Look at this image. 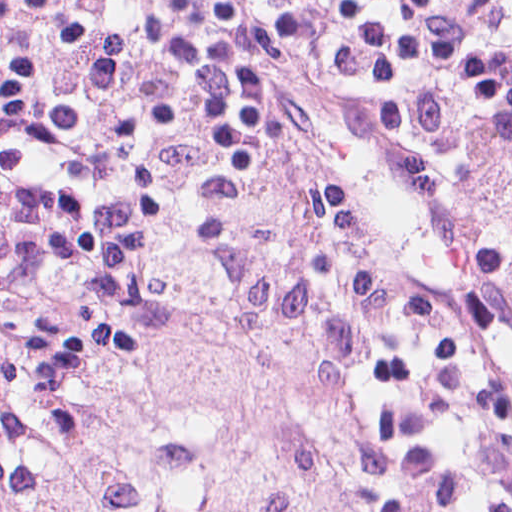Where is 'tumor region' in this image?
Returning a JSON list of instances; mask_svg holds the SVG:
<instances>
[{
	"label": "tumor region",
	"mask_w": 512,
	"mask_h": 512,
	"mask_svg": "<svg viewBox=\"0 0 512 512\" xmlns=\"http://www.w3.org/2000/svg\"><path fill=\"white\" fill-rule=\"evenodd\" d=\"M215 290L118 333L82 428L0 413L1 512H314L354 455L356 346L295 259L221 261Z\"/></svg>",
	"instance_id": "e687c5a6"
}]
</instances>
